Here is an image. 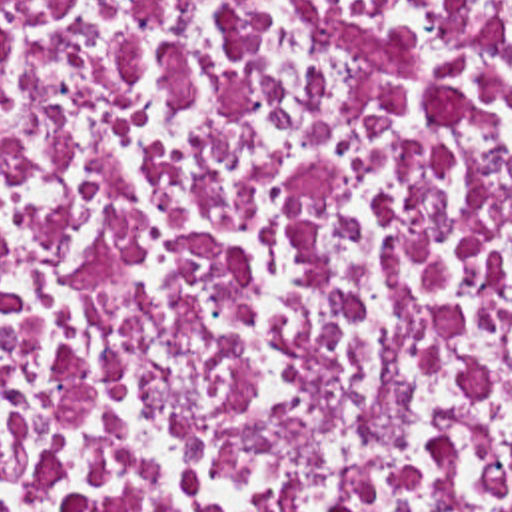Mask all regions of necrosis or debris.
<instances>
[{
  "label": "necrosis or debris",
  "instance_id": "obj_1",
  "mask_svg": "<svg viewBox=\"0 0 512 512\" xmlns=\"http://www.w3.org/2000/svg\"><path fill=\"white\" fill-rule=\"evenodd\" d=\"M0 512H512V0H0Z\"/></svg>",
  "mask_w": 512,
  "mask_h": 512
}]
</instances>
